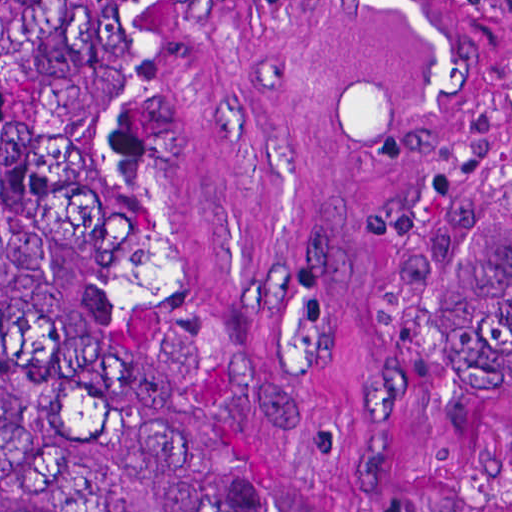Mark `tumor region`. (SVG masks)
<instances>
[{
    "mask_svg": "<svg viewBox=\"0 0 512 512\" xmlns=\"http://www.w3.org/2000/svg\"><path fill=\"white\" fill-rule=\"evenodd\" d=\"M430 253L512 447V132L430 142ZM0 512H361L238 287L192 0H0Z\"/></svg>",
    "mask_w": 512,
    "mask_h": 512,
    "instance_id": "obj_1",
    "label": "tumor region"
}]
</instances>
